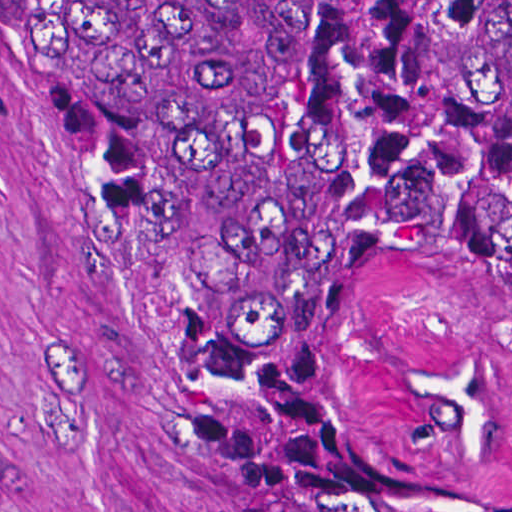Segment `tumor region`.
<instances>
[{
  "mask_svg": "<svg viewBox=\"0 0 512 512\" xmlns=\"http://www.w3.org/2000/svg\"><path fill=\"white\" fill-rule=\"evenodd\" d=\"M122 202L230 407V512H512L346 400L414 266L512 301V1H61Z\"/></svg>",
  "mask_w": 512,
  "mask_h": 512,
  "instance_id": "e687c5a6",
  "label": "tumor region"
}]
</instances>
